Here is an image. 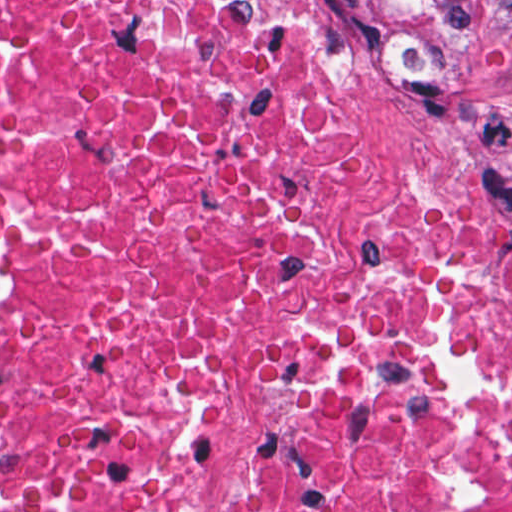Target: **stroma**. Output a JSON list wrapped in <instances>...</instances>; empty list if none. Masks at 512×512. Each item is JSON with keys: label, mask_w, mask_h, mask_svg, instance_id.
Returning a JSON list of instances; mask_svg holds the SVG:
<instances>
[{"label": "stroma", "mask_w": 512, "mask_h": 512, "mask_svg": "<svg viewBox=\"0 0 512 512\" xmlns=\"http://www.w3.org/2000/svg\"><path fill=\"white\" fill-rule=\"evenodd\" d=\"M294 1L332 50L309 1ZM350 78L356 115L391 175L428 208L512 244V0H478L455 50L421 75Z\"/></svg>", "instance_id": "1"}]
</instances>
